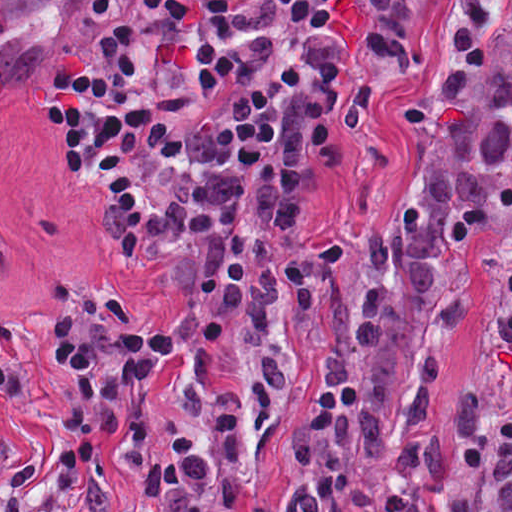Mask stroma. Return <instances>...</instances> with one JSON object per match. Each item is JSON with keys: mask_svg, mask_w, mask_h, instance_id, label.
<instances>
[{"mask_svg": "<svg viewBox=\"0 0 512 512\" xmlns=\"http://www.w3.org/2000/svg\"><path fill=\"white\" fill-rule=\"evenodd\" d=\"M91 0H0V366H19L0 408V510L26 463L43 458L32 501L47 512H154L143 487L149 463L181 435L215 447L216 421L176 403L165 389L225 343L252 303V283L278 258L319 250L335 258L352 309L364 291V249L408 180L420 100L452 43V0H433L424 66L375 62L364 27L373 0L307 39V85L284 118L280 159L249 189L264 250L225 322L209 338L188 331L185 310L201 287L206 246L184 235L140 261L103 228L104 201L70 166L63 135L50 133L38 83L67 51L89 43ZM506 225L468 239L451 312L437 399L447 449L511 422L485 381L482 328ZM62 287L91 338L155 332L172 323L160 380L144 385L119 435L95 440L96 459L70 497L56 484L74 384L53 359ZM304 367L293 371L260 453L265 512H306L288 463Z\"/></svg>", "mask_w": 512, "mask_h": 512, "instance_id": "1", "label": "stroma"}]
</instances>
